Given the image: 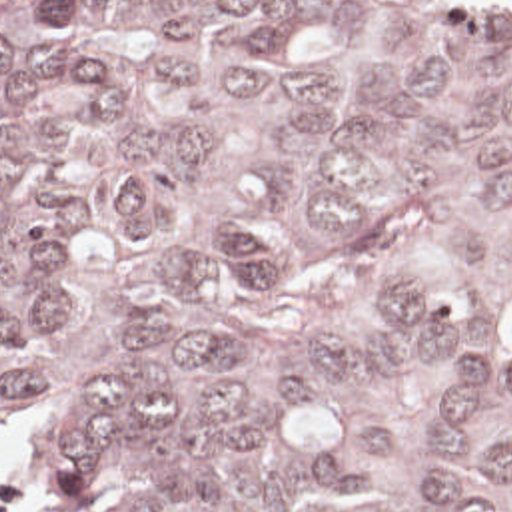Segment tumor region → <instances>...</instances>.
Returning <instances> with one entry per match:
<instances>
[{"label":"tumor region","instance_id":"e687c5a6","mask_svg":"<svg viewBox=\"0 0 512 512\" xmlns=\"http://www.w3.org/2000/svg\"><path fill=\"white\" fill-rule=\"evenodd\" d=\"M40 512H512V0H0V430Z\"/></svg>","mask_w":512,"mask_h":512}]
</instances>
